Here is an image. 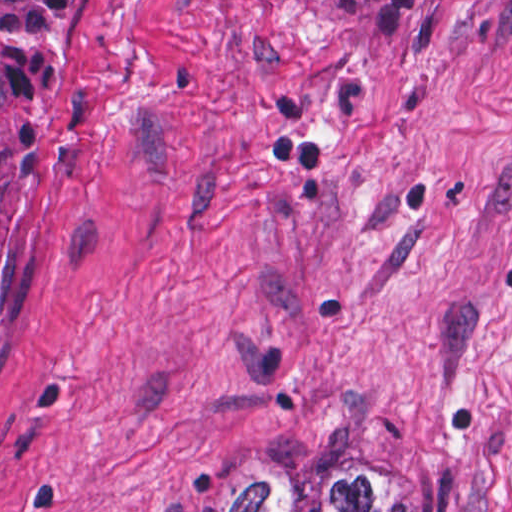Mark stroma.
I'll return each mask as SVG.
<instances>
[{
    "label": "stroma",
    "mask_w": 512,
    "mask_h": 512,
    "mask_svg": "<svg viewBox=\"0 0 512 512\" xmlns=\"http://www.w3.org/2000/svg\"><path fill=\"white\" fill-rule=\"evenodd\" d=\"M81 1L0 330V512L512 470V0Z\"/></svg>",
    "instance_id": "35a3bbf8"
}]
</instances>
